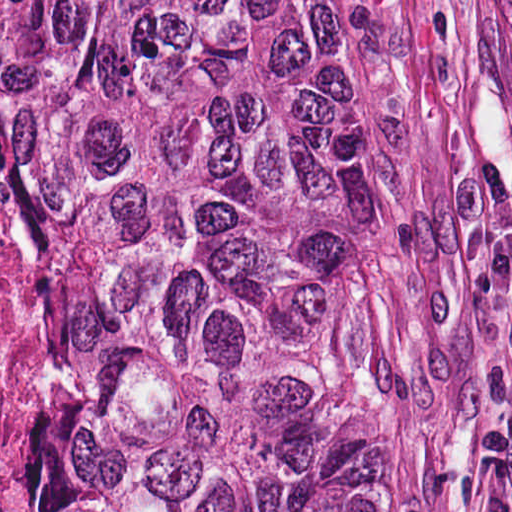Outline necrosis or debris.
Segmentation results:
<instances>
[{"label": "necrosis or debris", "mask_w": 512, "mask_h": 512, "mask_svg": "<svg viewBox=\"0 0 512 512\" xmlns=\"http://www.w3.org/2000/svg\"><path fill=\"white\" fill-rule=\"evenodd\" d=\"M46 421L41 380L4 286L0 232V512H13L18 489V434Z\"/></svg>", "instance_id": "1"}]
</instances>
